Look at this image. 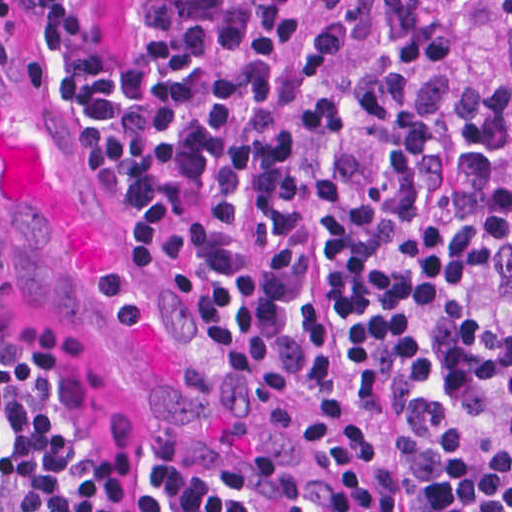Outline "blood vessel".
Returning <instances> with one entry per match:
<instances>
[{"label": "blood vessel", "instance_id": "obj_1", "mask_svg": "<svg viewBox=\"0 0 512 512\" xmlns=\"http://www.w3.org/2000/svg\"><path fill=\"white\" fill-rule=\"evenodd\" d=\"M0 285L97 358L171 466L245 512H351L1 66Z\"/></svg>", "mask_w": 512, "mask_h": 512}]
</instances>
